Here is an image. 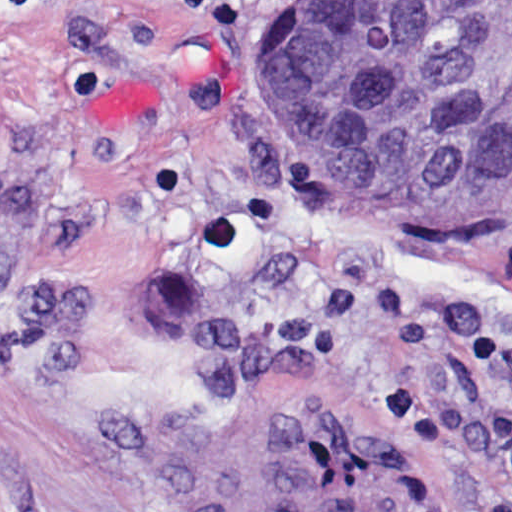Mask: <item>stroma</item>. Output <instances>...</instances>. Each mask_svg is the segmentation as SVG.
I'll return each instance as SVG.
<instances>
[{"label": "stroma", "mask_w": 512, "mask_h": 512, "mask_svg": "<svg viewBox=\"0 0 512 512\" xmlns=\"http://www.w3.org/2000/svg\"><path fill=\"white\" fill-rule=\"evenodd\" d=\"M286 0H0V512H512V205L320 180Z\"/></svg>", "instance_id": "1"}]
</instances>
